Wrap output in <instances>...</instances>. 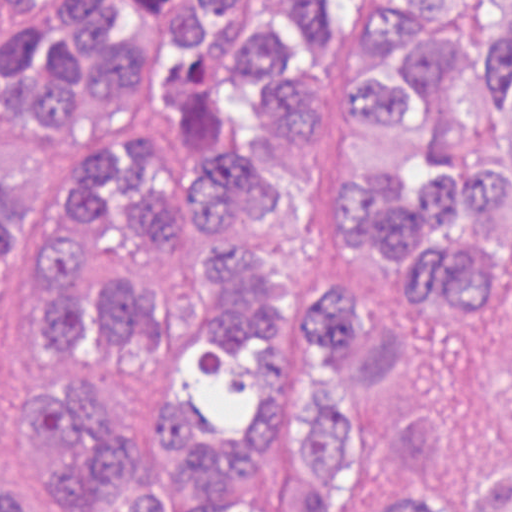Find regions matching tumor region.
<instances>
[{"instance_id": "1", "label": "tumor region", "mask_w": 512, "mask_h": 512, "mask_svg": "<svg viewBox=\"0 0 512 512\" xmlns=\"http://www.w3.org/2000/svg\"><path fill=\"white\" fill-rule=\"evenodd\" d=\"M26 0H0V6ZM134 0H51L0 32V101L61 131L75 86L137 82L140 45L115 34ZM160 101L176 105L194 169L184 184L198 244L158 293L118 272L82 297L74 269L100 213L142 244L176 237V190L152 170L161 139L120 160L87 151L63 187L66 236L39 246L51 291L29 314L47 351L81 355L102 334L133 357L173 335L170 299L208 242L209 322L193 325L130 395L88 379L29 376L0 389V446L32 448L66 512H512V472L467 509L424 476L377 465V435L341 336V287L290 301L213 228L233 203L262 215L264 185L228 143L276 102L307 137L332 237L406 307L389 346L409 451L462 376L512 272V0H175ZM27 251V175L0 166V335ZM275 313L293 323L267 322ZM0 512H31L0 471Z\"/></svg>"}]
</instances>
